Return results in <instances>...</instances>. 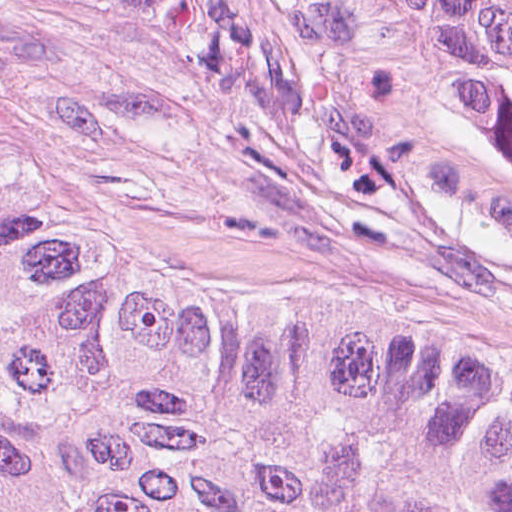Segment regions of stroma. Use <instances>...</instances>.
I'll use <instances>...</instances> for the list:
<instances>
[{
	"instance_id": "35a3bbf8",
	"label": "stroma",
	"mask_w": 512,
	"mask_h": 512,
	"mask_svg": "<svg viewBox=\"0 0 512 512\" xmlns=\"http://www.w3.org/2000/svg\"><path fill=\"white\" fill-rule=\"evenodd\" d=\"M0 144L124 260L512 381V173L295 0H0Z\"/></svg>"
}]
</instances>
